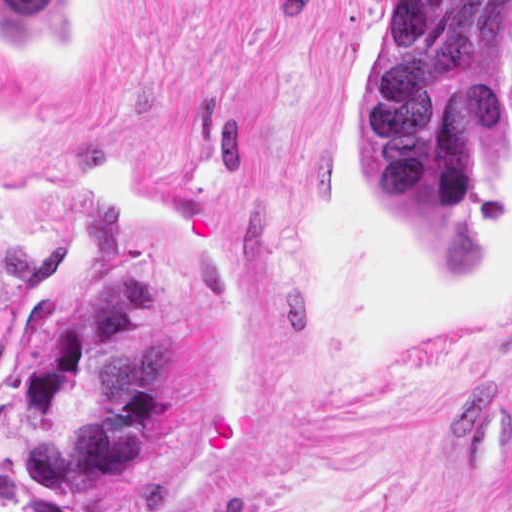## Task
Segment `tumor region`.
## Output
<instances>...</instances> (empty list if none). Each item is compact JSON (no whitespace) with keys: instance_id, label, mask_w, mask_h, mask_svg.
<instances>
[{"instance_id":"e687c5a6","label":"tumor region","mask_w":512,"mask_h":512,"mask_svg":"<svg viewBox=\"0 0 512 512\" xmlns=\"http://www.w3.org/2000/svg\"><path fill=\"white\" fill-rule=\"evenodd\" d=\"M396 4L398 39L365 105V175L458 273L480 260L477 161L498 147L491 1ZM82 1H0V39L67 60ZM14 393V449L53 498H86L125 472L170 395V341L150 265L118 260L88 301L37 334Z\"/></svg>"}]
</instances>
